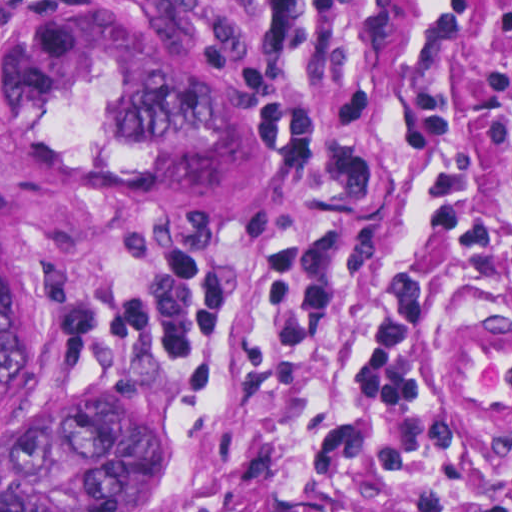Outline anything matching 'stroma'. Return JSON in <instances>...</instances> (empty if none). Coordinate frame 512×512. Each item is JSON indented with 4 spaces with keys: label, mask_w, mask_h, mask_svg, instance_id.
I'll return each instance as SVG.
<instances>
[{
    "label": "stroma",
    "mask_w": 512,
    "mask_h": 512,
    "mask_svg": "<svg viewBox=\"0 0 512 512\" xmlns=\"http://www.w3.org/2000/svg\"><path fill=\"white\" fill-rule=\"evenodd\" d=\"M18 1H171L201 18L270 88L302 103L309 164L287 209L265 219L181 226H122L63 207L14 171L0 143V188L25 241L28 264L49 293L67 361L113 352L67 324L60 304L77 284L159 251H238L277 237L310 200L316 154L358 116V140L381 178L368 222L365 270L323 322L270 316L268 285L238 253L229 267V307L218 347L220 392L235 449L211 486L223 512H280L300 490L315 450L341 417V382L359 345V313L390 276L429 282V345L480 333L512 335V267L490 282L462 263L430 223L403 148V93L444 86L512 65V0H0V32ZM456 145L512 253V145L494 139V106L459 83L452 105ZM157 365L177 413L180 445L163 486L114 512H188L221 444L224 403L204 369L183 355L134 352ZM470 468L512 479V398L443 401ZM314 512H421L415 491L385 480L346 489L330 480L309 499Z\"/></svg>",
    "instance_id": "stroma-1"
}]
</instances>
